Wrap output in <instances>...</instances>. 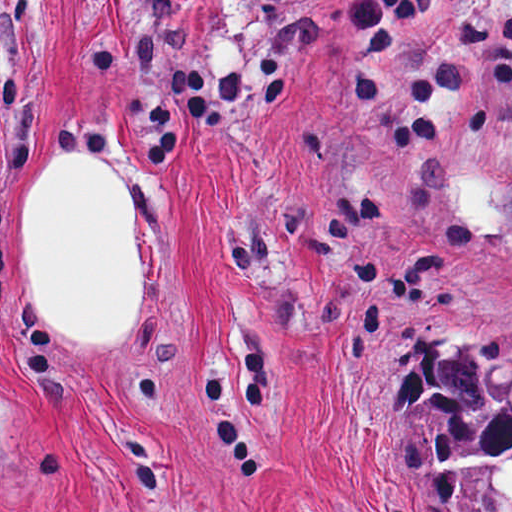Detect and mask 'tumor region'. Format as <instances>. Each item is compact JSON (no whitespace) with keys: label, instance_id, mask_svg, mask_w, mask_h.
Returning <instances> with one entry per match:
<instances>
[{"label":"tumor region","instance_id":"1","mask_svg":"<svg viewBox=\"0 0 512 512\" xmlns=\"http://www.w3.org/2000/svg\"><path fill=\"white\" fill-rule=\"evenodd\" d=\"M425 335L409 407L436 512H512V341L463 313Z\"/></svg>","mask_w":512,"mask_h":512}]
</instances>
